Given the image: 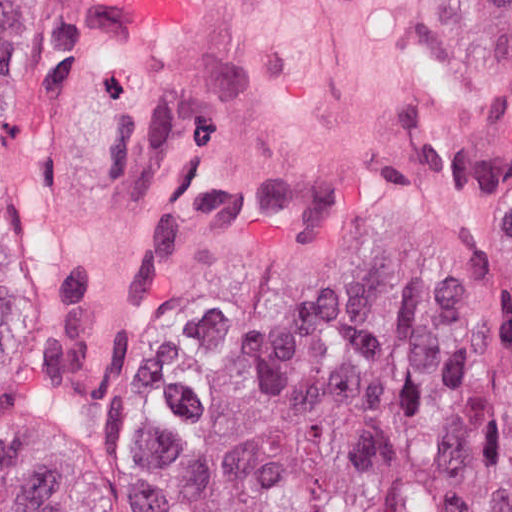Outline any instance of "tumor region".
I'll use <instances>...</instances> for the list:
<instances>
[{
    "label": "tumor region",
    "instance_id": "1",
    "mask_svg": "<svg viewBox=\"0 0 512 512\" xmlns=\"http://www.w3.org/2000/svg\"><path fill=\"white\" fill-rule=\"evenodd\" d=\"M29 0H0L3 112ZM0 512H50L0 388ZM183 512H512V316L426 276H372L209 394Z\"/></svg>",
    "mask_w": 512,
    "mask_h": 512
}]
</instances>
